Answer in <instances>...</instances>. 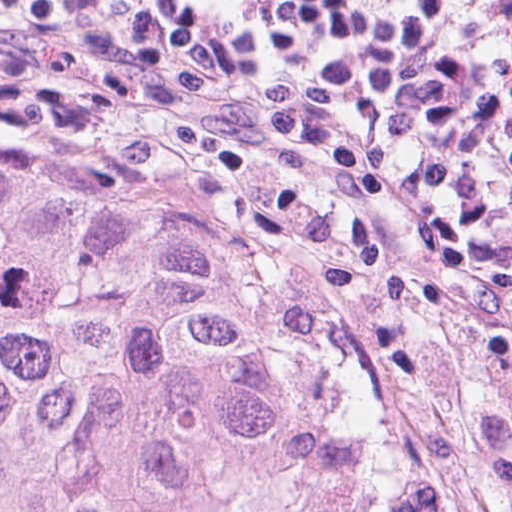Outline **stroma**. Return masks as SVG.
I'll list each match as a JSON object with an SVG mask.
<instances>
[{
  "mask_svg": "<svg viewBox=\"0 0 512 512\" xmlns=\"http://www.w3.org/2000/svg\"><path fill=\"white\" fill-rule=\"evenodd\" d=\"M0 132H107L152 155L214 257L303 305L449 412L482 512H512L474 443L478 408L512 413V317L491 290L430 280L362 214L252 158L178 86L105 81L0 50Z\"/></svg>",
  "mask_w": 512,
  "mask_h": 512,
  "instance_id": "stroma-1",
  "label": "stroma"
}]
</instances>
